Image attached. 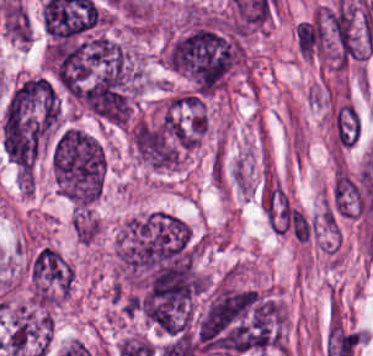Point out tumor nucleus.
Returning <instances> with one entry per match:
<instances>
[{
    "instance_id": "1",
    "label": "tumor nucleus",
    "mask_w": 373,
    "mask_h": 356,
    "mask_svg": "<svg viewBox=\"0 0 373 356\" xmlns=\"http://www.w3.org/2000/svg\"><path fill=\"white\" fill-rule=\"evenodd\" d=\"M242 42L228 22L196 17L164 50L168 68L196 91L211 94L238 66Z\"/></svg>"
},
{
    "instance_id": "2",
    "label": "tumor nucleus",
    "mask_w": 373,
    "mask_h": 356,
    "mask_svg": "<svg viewBox=\"0 0 373 356\" xmlns=\"http://www.w3.org/2000/svg\"><path fill=\"white\" fill-rule=\"evenodd\" d=\"M59 98L49 79L22 77L11 89L0 118L1 143L7 155H36L52 136Z\"/></svg>"
},
{
    "instance_id": "3",
    "label": "tumor nucleus",
    "mask_w": 373,
    "mask_h": 356,
    "mask_svg": "<svg viewBox=\"0 0 373 356\" xmlns=\"http://www.w3.org/2000/svg\"><path fill=\"white\" fill-rule=\"evenodd\" d=\"M189 244V227L170 214L153 211L122 225L115 255L127 279L136 282Z\"/></svg>"
},
{
    "instance_id": "4",
    "label": "tumor nucleus",
    "mask_w": 373,
    "mask_h": 356,
    "mask_svg": "<svg viewBox=\"0 0 373 356\" xmlns=\"http://www.w3.org/2000/svg\"><path fill=\"white\" fill-rule=\"evenodd\" d=\"M51 160L54 182L66 198L83 206L96 199L106 168L96 137L74 125L63 127L53 141Z\"/></svg>"
},
{
    "instance_id": "5",
    "label": "tumor nucleus",
    "mask_w": 373,
    "mask_h": 356,
    "mask_svg": "<svg viewBox=\"0 0 373 356\" xmlns=\"http://www.w3.org/2000/svg\"><path fill=\"white\" fill-rule=\"evenodd\" d=\"M30 283L36 305H55L70 290V265L55 247L42 244L31 258Z\"/></svg>"
}]
</instances>
